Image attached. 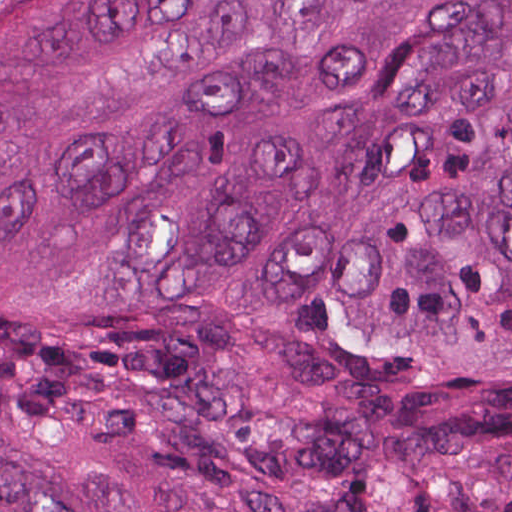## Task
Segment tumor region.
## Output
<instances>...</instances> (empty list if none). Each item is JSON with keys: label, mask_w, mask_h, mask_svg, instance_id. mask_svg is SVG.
<instances>
[{"label": "tumor region", "mask_w": 512, "mask_h": 512, "mask_svg": "<svg viewBox=\"0 0 512 512\" xmlns=\"http://www.w3.org/2000/svg\"><path fill=\"white\" fill-rule=\"evenodd\" d=\"M0 512H512V1H0Z\"/></svg>", "instance_id": "1"}]
</instances>
